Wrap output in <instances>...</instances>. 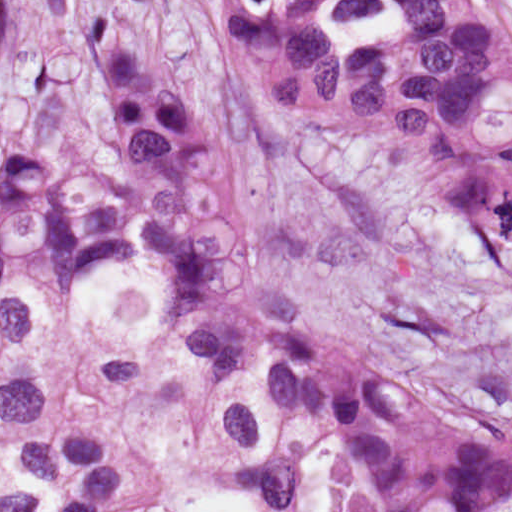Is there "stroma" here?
Instances as JSON below:
<instances>
[{
  "mask_svg": "<svg viewBox=\"0 0 512 512\" xmlns=\"http://www.w3.org/2000/svg\"><path fill=\"white\" fill-rule=\"evenodd\" d=\"M156 8L242 197L260 267L334 314L376 361L512 439V264L492 229L419 211L350 141L292 123L264 98L213 0ZM102 29L96 0H0V110L65 141L85 135L94 115L78 69ZM84 328L138 369L148 391L106 393L57 356L37 353L26 366L56 424L135 442L142 459L115 512L197 486L246 489L226 470L152 294L102 285L88 297ZM339 489L316 428L300 501L287 512H336Z\"/></svg>",
  "mask_w": 512,
  "mask_h": 512,
  "instance_id": "stroma-1",
  "label": "stroma"
}]
</instances>
